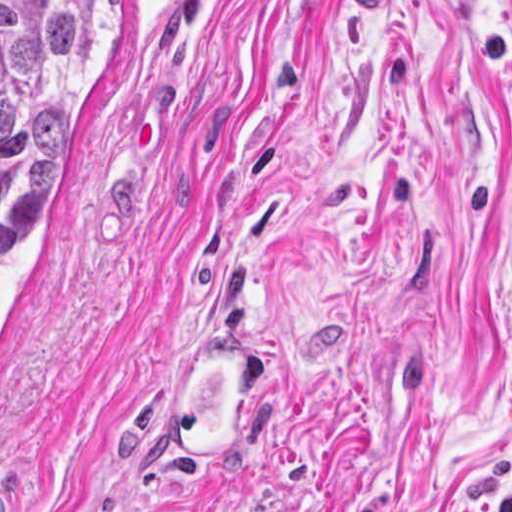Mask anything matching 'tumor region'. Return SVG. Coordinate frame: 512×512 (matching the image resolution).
I'll return each instance as SVG.
<instances>
[{"label": "tumor region", "mask_w": 512, "mask_h": 512, "mask_svg": "<svg viewBox=\"0 0 512 512\" xmlns=\"http://www.w3.org/2000/svg\"><path fill=\"white\" fill-rule=\"evenodd\" d=\"M103 1H0V242L64 172L71 90Z\"/></svg>", "instance_id": "e687c5a6"}]
</instances>
